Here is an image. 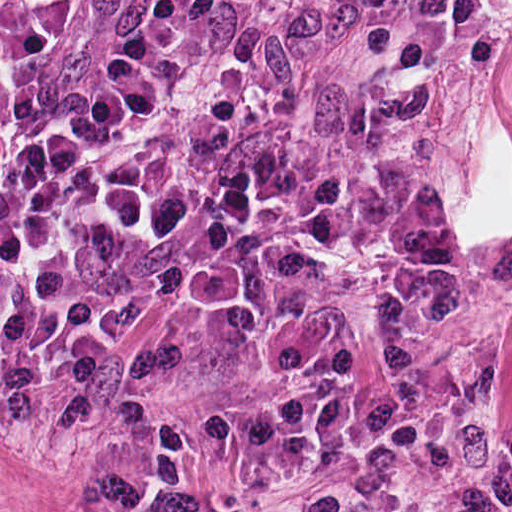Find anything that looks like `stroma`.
Here are the masks:
<instances>
[{
  "instance_id": "35a3bbf8",
  "label": "stroma",
  "mask_w": 512,
  "mask_h": 512,
  "mask_svg": "<svg viewBox=\"0 0 512 512\" xmlns=\"http://www.w3.org/2000/svg\"><path fill=\"white\" fill-rule=\"evenodd\" d=\"M137 0H97L0 92V123L52 109ZM261 0H202L184 66L159 108L111 156L166 188L177 228L113 262L100 303L109 376L58 426L0 423V512H95Z\"/></svg>"
}]
</instances>
